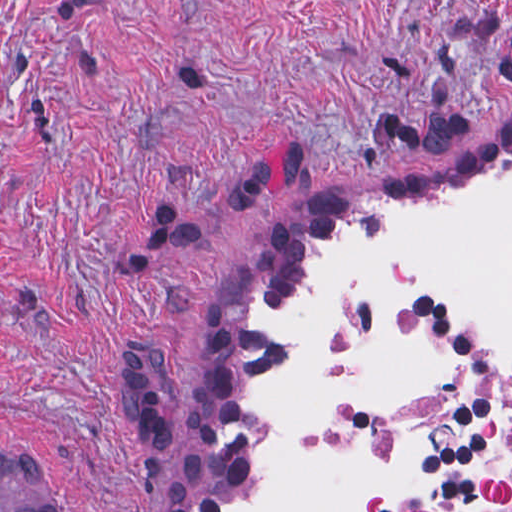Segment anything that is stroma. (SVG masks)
<instances>
[{
    "label": "stroma",
    "mask_w": 512,
    "mask_h": 512,
    "mask_svg": "<svg viewBox=\"0 0 512 512\" xmlns=\"http://www.w3.org/2000/svg\"><path fill=\"white\" fill-rule=\"evenodd\" d=\"M512 140V0H0V449L58 512H202L248 287Z\"/></svg>",
    "instance_id": "1"
}]
</instances>
